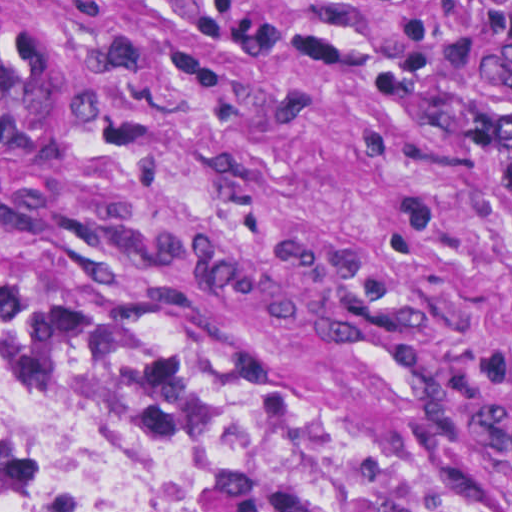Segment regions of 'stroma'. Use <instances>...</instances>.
I'll use <instances>...</instances> for the list:
<instances>
[{"mask_svg":"<svg viewBox=\"0 0 512 512\" xmlns=\"http://www.w3.org/2000/svg\"><path fill=\"white\" fill-rule=\"evenodd\" d=\"M230 1L354 44L372 72L418 16L422 85L393 107L287 49L193 30L170 0H0L10 19L158 44L69 177L0 163V322L277 395L512 512V192L439 123L473 102L455 51L475 8Z\"/></svg>","mask_w":512,"mask_h":512,"instance_id":"35a3bbf8","label":"stroma"}]
</instances>
